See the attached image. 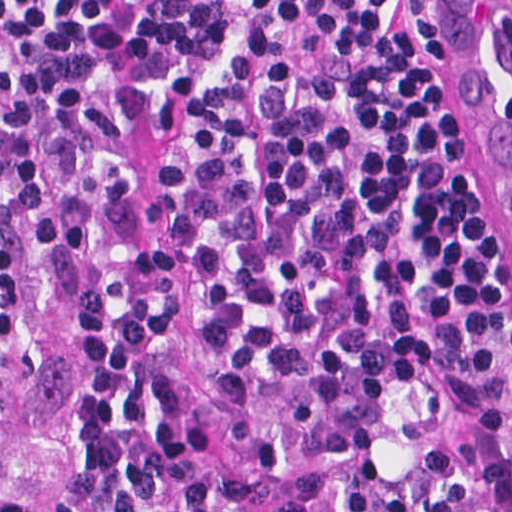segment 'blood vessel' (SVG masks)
I'll list each match as a JSON object with an SVG mask.
<instances>
[{
    "instance_id": "blood-vessel-1",
    "label": "blood vessel",
    "mask_w": 512,
    "mask_h": 512,
    "mask_svg": "<svg viewBox=\"0 0 512 512\" xmlns=\"http://www.w3.org/2000/svg\"><path fill=\"white\" fill-rule=\"evenodd\" d=\"M446 2L491 128L496 169L512 214V0Z\"/></svg>"
}]
</instances>
